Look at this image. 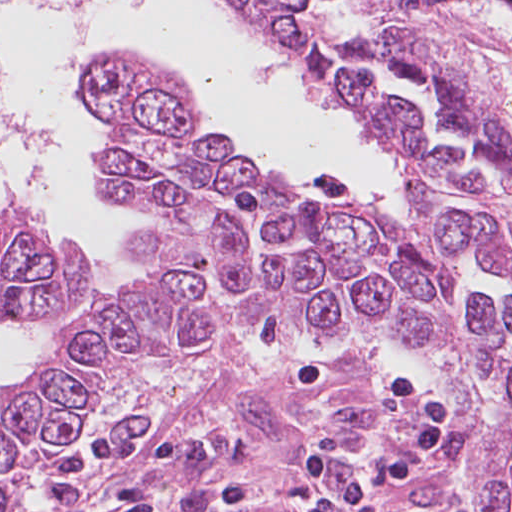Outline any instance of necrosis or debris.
Listing matches in <instances>:
<instances>
[{
	"mask_svg": "<svg viewBox=\"0 0 512 512\" xmlns=\"http://www.w3.org/2000/svg\"><path fill=\"white\" fill-rule=\"evenodd\" d=\"M33 1L53 8L67 30H89L97 21L104 0H0V4Z\"/></svg>",
	"mask_w": 512,
	"mask_h": 512,
	"instance_id": "4bbe7bcc",
	"label": "necrosis or debris"
}]
</instances>
